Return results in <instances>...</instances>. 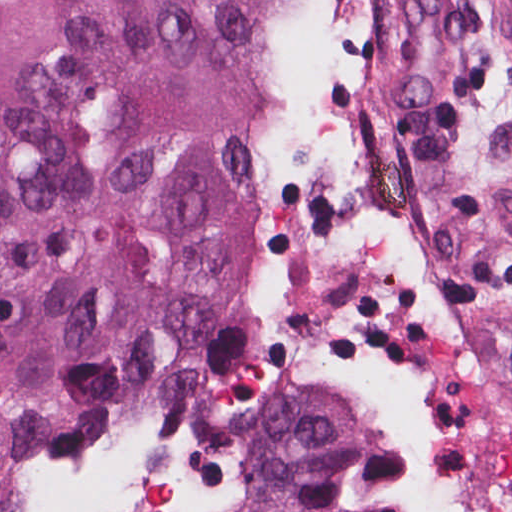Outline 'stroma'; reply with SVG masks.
I'll list each match as a JSON object with an SVG mask.
<instances>
[{"label": "stroma", "instance_id": "35a3bbf8", "mask_svg": "<svg viewBox=\"0 0 512 512\" xmlns=\"http://www.w3.org/2000/svg\"><path fill=\"white\" fill-rule=\"evenodd\" d=\"M455 2L456 61L412 112L392 110L375 78L367 0L331 7L344 110L409 165L426 199L430 265L465 353L476 420L470 494L449 510L423 501L396 463L368 503L381 512H512V7ZM0 512L14 511L0 501ZM52 512H111L108 439Z\"/></svg>", "mask_w": 512, "mask_h": 512}]
</instances>
